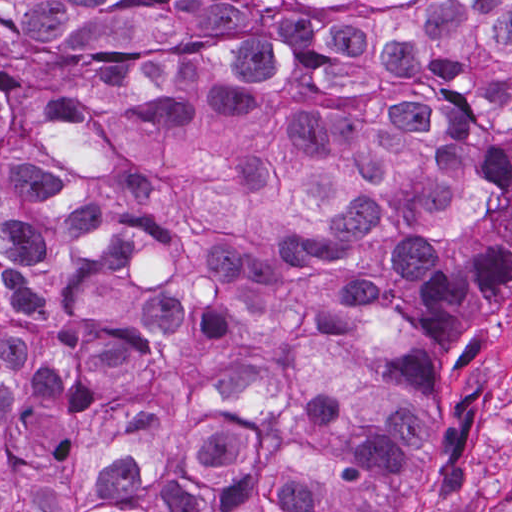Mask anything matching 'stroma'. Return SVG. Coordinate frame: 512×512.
Listing matches in <instances>:
<instances>
[{
    "label": "stroma",
    "instance_id": "obj_1",
    "mask_svg": "<svg viewBox=\"0 0 512 512\" xmlns=\"http://www.w3.org/2000/svg\"><path fill=\"white\" fill-rule=\"evenodd\" d=\"M453 393H470L465 443L442 478L465 512H501L512 480V292L448 359ZM0 512H1V0H0Z\"/></svg>",
    "mask_w": 512,
    "mask_h": 512
}]
</instances>
